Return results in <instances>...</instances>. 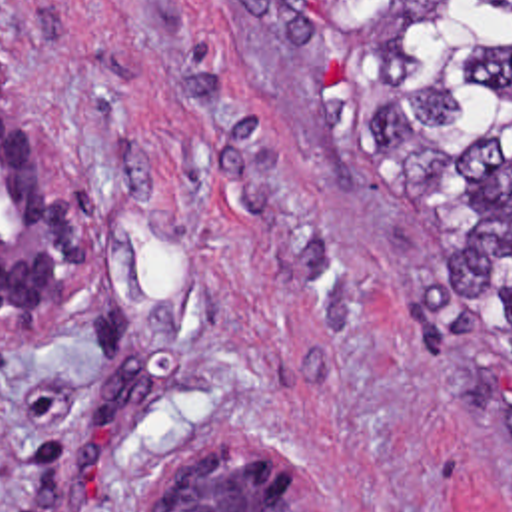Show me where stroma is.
<instances>
[{"label": "stroma", "mask_w": 512, "mask_h": 512, "mask_svg": "<svg viewBox=\"0 0 512 512\" xmlns=\"http://www.w3.org/2000/svg\"><path fill=\"white\" fill-rule=\"evenodd\" d=\"M0 54L95 238L0 320V512H143L165 461L251 443L319 512H512L481 322L301 52L225 0H0Z\"/></svg>", "instance_id": "stroma-1"}]
</instances>
